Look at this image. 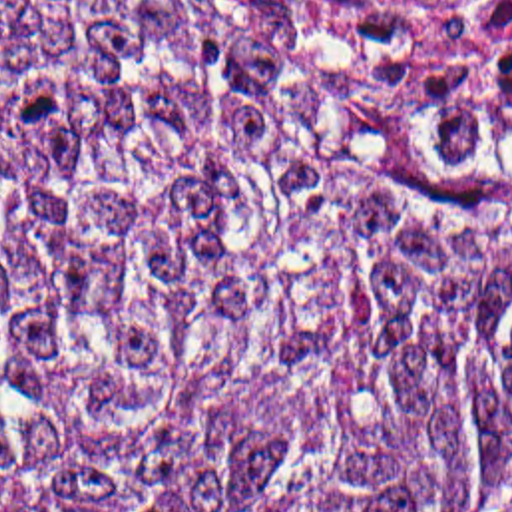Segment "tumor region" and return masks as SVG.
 Returning <instances> with one entry per match:
<instances>
[{"mask_svg":"<svg viewBox=\"0 0 512 512\" xmlns=\"http://www.w3.org/2000/svg\"><path fill=\"white\" fill-rule=\"evenodd\" d=\"M0 512H512V175L335 47L0 0Z\"/></svg>","mask_w":512,"mask_h":512,"instance_id":"tumor-region-1","label":"tumor region"}]
</instances>
